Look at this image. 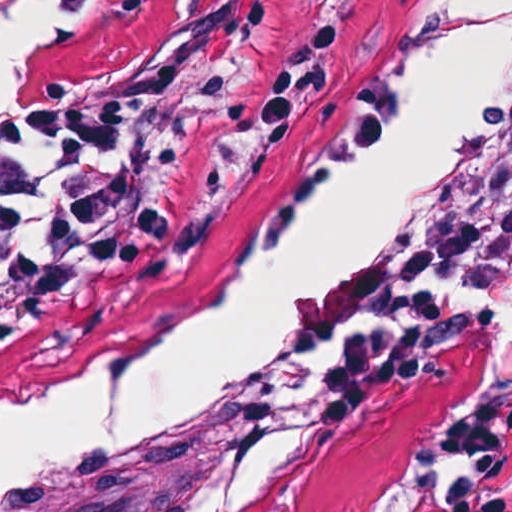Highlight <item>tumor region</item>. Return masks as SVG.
Returning a JSON list of instances; mask_svg holds the SVG:
<instances>
[{"label": "tumor region", "instance_id": "e687c5a6", "mask_svg": "<svg viewBox=\"0 0 512 512\" xmlns=\"http://www.w3.org/2000/svg\"><path fill=\"white\" fill-rule=\"evenodd\" d=\"M512 280V130L423 194L382 247L370 307L446 323Z\"/></svg>", "mask_w": 512, "mask_h": 512}]
</instances>
